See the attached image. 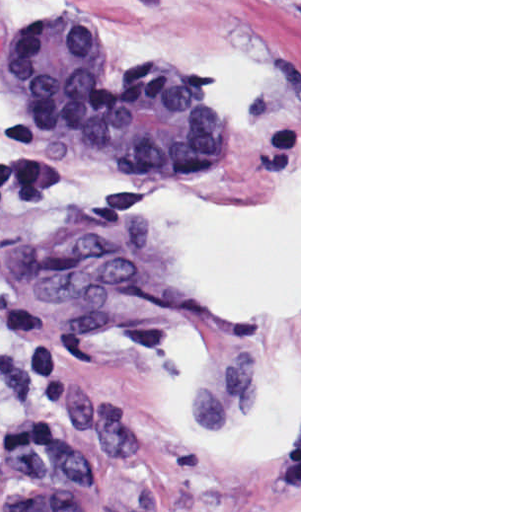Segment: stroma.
<instances>
[{
  "label": "stroma",
  "instance_id": "stroma-1",
  "mask_svg": "<svg viewBox=\"0 0 512 512\" xmlns=\"http://www.w3.org/2000/svg\"><path fill=\"white\" fill-rule=\"evenodd\" d=\"M57 21L113 73H212L227 140L181 179L92 160L0 49L2 168L34 148L81 182L144 184L123 214L7 221L0 290L47 311L67 381L36 386L0 343V512L55 434L86 450L97 512H301V0H0V45Z\"/></svg>",
  "mask_w": 512,
  "mask_h": 512
}]
</instances>
